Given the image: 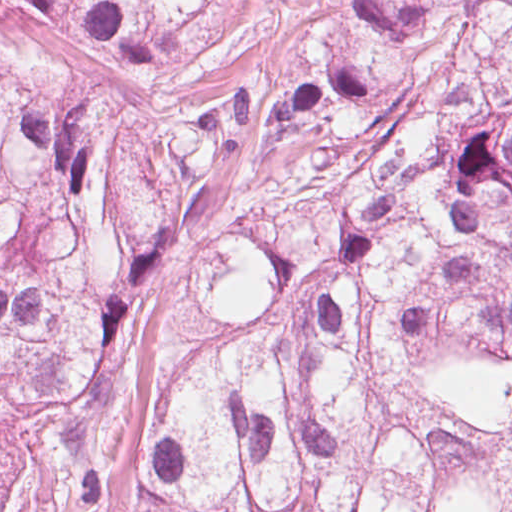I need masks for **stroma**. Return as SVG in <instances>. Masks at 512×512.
Returning a JSON list of instances; mask_svg holds the SVG:
<instances>
[{
    "label": "stroma",
    "mask_w": 512,
    "mask_h": 512,
    "mask_svg": "<svg viewBox=\"0 0 512 512\" xmlns=\"http://www.w3.org/2000/svg\"><path fill=\"white\" fill-rule=\"evenodd\" d=\"M14 512H61L60 503L33 486H19Z\"/></svg>",
    "instance_id": "1"
}]
</instances>
